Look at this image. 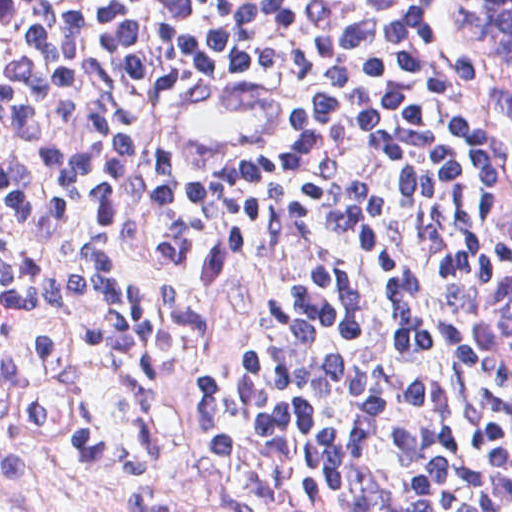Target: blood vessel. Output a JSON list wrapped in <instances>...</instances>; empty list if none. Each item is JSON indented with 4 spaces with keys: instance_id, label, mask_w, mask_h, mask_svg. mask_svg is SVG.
Segmentation results:
<instances>
[{
    "instance_id": "obj_1",
    "label": "blood vessel",
    "mask_w": 512,
    "mask_h": 512,
    "mask_svg": "<svg viewBox=\"0 0 512 512\" xmlns=\"http://www.w3.org/2000/svg\"><path fill=\"white\" fill-rule=\"evenodd\" d=\"M167 113L180 136L204 151L267 152L294 138L289 93L255 71L177 78L167 91Z\"/></svg>"
}]
</instances>
